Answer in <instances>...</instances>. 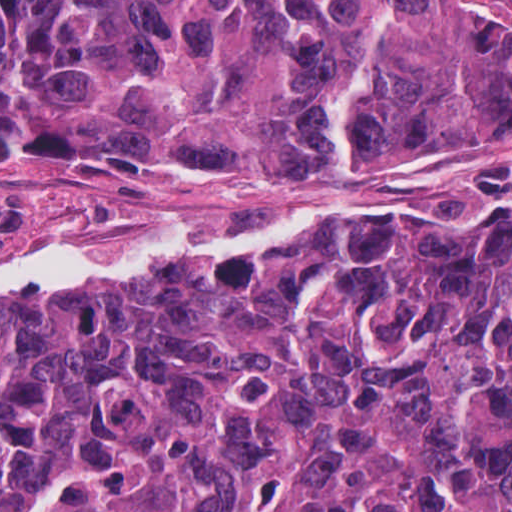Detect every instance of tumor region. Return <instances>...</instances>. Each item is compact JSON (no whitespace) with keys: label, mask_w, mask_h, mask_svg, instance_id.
<instances>
[{"label":"tumor region","mask_w":512,"mask_h":512,"mask_svg":"<svg viewBox=\"0 0 512 512\" xmlns=\"http://www.w3.org/2000/svg\"><path fill=\"white\" fill-rule=\"evenodd\" d=\"M512 111V3L0 0V157L208 176ZM352 225L0 296V512H512V209ZM255 233L258 226L137 225Z\"/></svg>","instance_id":"1"}]
</instances>
